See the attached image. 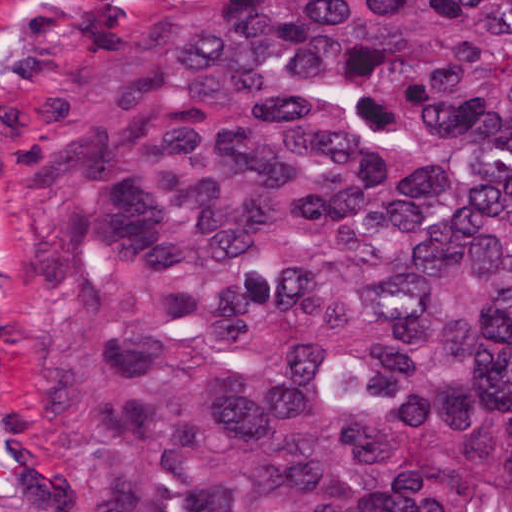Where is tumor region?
<instances>
[{
  "label": "tumor region",
  "mask_w": 512,
  "mask_h": 512,
  "mask_svg": "<svg viewBox=\"0 0 512 512\" xmlns=\"http://www.w3.org/2000/svg\"><path fill=\"white\" fill-rule=\"evenodd\" d=\"M1 413L65 512H512V0H10Z\"/></svg>",
  "instance_id": "obj_1"
}]
</instances>
